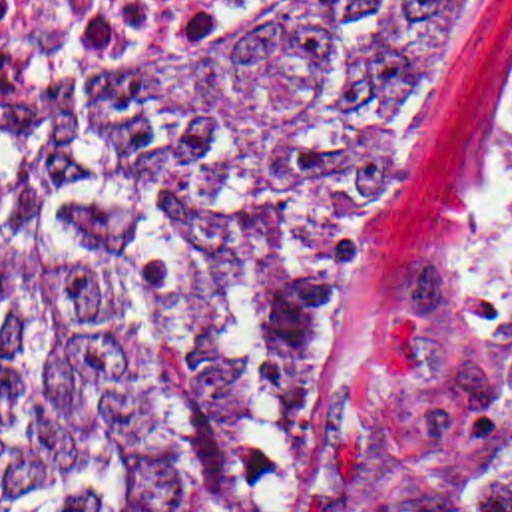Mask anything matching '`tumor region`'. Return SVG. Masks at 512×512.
<instances>
[{"mask_svg":"<svg viewBox=\"0 0 512 512\" xmlns=\"http://www.w3.org/2000/svg\"><path fill=\"white\" fill-rule=\"evenodd\" d=\"M458 39L460 0L309 3L133 81L0 97V167L283 342ZM295 511V398L0 177V512ZM363 512H512V380L402 410Z\"/></svg>","mask_w":512,"mask_h":512,"instance_id":"obj_1","label":"tumor region"}]
</instances>
